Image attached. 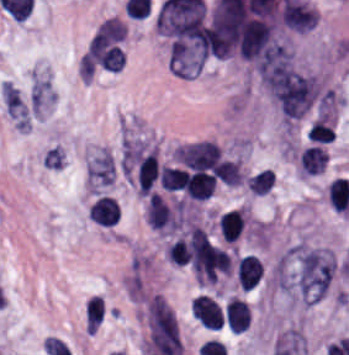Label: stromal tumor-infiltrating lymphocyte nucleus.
<instances>
[{"mask_svg":"<svg viewBox=\"0 0 349 355\" xmlns=\"http://www.w3.org/2000/svg\"><path fill=\"white\" fill-rule=\"evenodd\" d=\"M263 273V266L257 256L246 253L236 263L237 281L243 289H251Z\"/></svg>","mask_w":349,"mask_h":355,"instance_id":"3290ff9b","label":"stromal tumor-infiltrating lymphocyte nucleus"},{"mask_svg":"<svg viewBox=\"0 0 349 355\" xmlns=\"http://www.w3.org/2000/svg\"><path fill=\"white\" fill-rule=\"evenodd\" d=\"M225 313L228 328L237 333L246 331L248 326V305L246 303L233 296L226 304Z\"/></svg>","mask_w":349,"mask_h":355,"instance_id":"9ea309e8","label":"stromal tumor-infiltrating lymphocyte nucleus"},{"mask_svg":"<svg viewBox=\"0 0 349 355\" xmlns=\"http://www.w3.org/2000/svg\"><path fill=\"white\" fill-rule=\"evenodd\" d=\"M327 160L326 151L317 143L306 146L300 151L298 164L300 170L307 174L322 172Z\"/></svg>","mask_w":349,"mask_h":355,"instance_id":"abfb95fc","label":"stromal tumor-infiltrating lymphocyte nucleus"},{"mask_svg":"<svg viewBox=\"0 0 349 355\" xmlns=\"http://www.w3.org/2000/svg\"><path fill=\"white\" fill-rule=\"evenodd\" d=\"M244 222V209L228 211L219 218V229L224 239L230 243L241 235Z\"/></svg>","mask_w":349,"mask_h":355,"instance_id":"f3e2335f","label":"stromal tumor-infiltrating lymphocyte nucleus"},{"mask_svg":"<svg viewBox=\"0 0 349 355\" xmlns=\"http://www.w3.org/2000/svg\"><path fill=\"white\" fill-rule=\"evenodd\" d=\"M327 200L340 211L349 210V182L347 178H333L327 186Z\"/></svg>","mask_w":349,"mask_h":355,"instance_id":"4f13568d","label":"stromal tumor-infiltrating lymphocyte nucleus"},{"mask_svg":"<svg viewBox=\"0 0 349 355\" xmlns=\"http://www.w3.org/2000/svg\"><path fill=\"white\" fill-rule=\"evenodd\" d=\"M159 170L157 150L154 148L137 161L136 181L138 195H145L152 187Z\"/></svg>","mask_w":349,"mask_h":355,"instance_id":"bc302bb0","label":"stromal tumor-infiltrating lymphocyte nucleus"},{"mask_svg":"<svg viewBox=\"0 0 349 355\" xmlns=\"http://www.w3.org/2000/svg\"><path fill=\"white\" fill-rule=\"evenodd\" d=\"M334 132L326 121L321 117L314 120L306 131V138L311 141L329 142Z\"/></svg>","mask_w":349,"mask_h":355,"instance_id":"2a367800","label":"stromal tumor-infiltrating lymphocyte nucleus"},{"mask_svg":"<svg viewBox=\"0 0 349 355\" xmlns=\"http://www.w3.org/2000/svg\"><path fill=\"white\" fill-rule=\"evenodd\" d=\"M89 220L101 225H115L120 213L113 198L100 195L94 200L88 210Z\"/></svg>","mask_w":349,"mask_h":355,"instance_id":"52c7bb5b","label":"stromal tumor-infiltrating lymphocyte nucleus"},{"mask_svg":"<svg viewBox=\"0 0 349 355\" xmlns=\"http://www.w3.org/2000/svg\"><path fill=\"white\" fill-rule=\"evenodd\" d=\"M216 186V179L213 181H210L208 183H205L201 186H198L194 189H191L189 191L184 192L187 197H189L191 200H205L208 198L212 192L214 191Z\"/></svg>","mask_w":349,"mask_h":355,"instance_id":"4803ca6d","label":"stromal tumor-infiltrating lymphocyte nucleus"}]
</instances>
